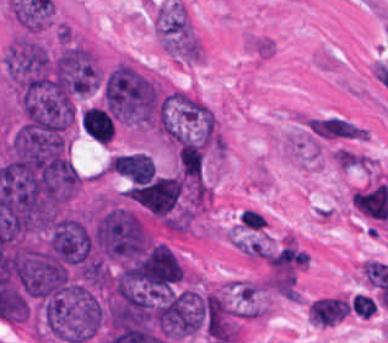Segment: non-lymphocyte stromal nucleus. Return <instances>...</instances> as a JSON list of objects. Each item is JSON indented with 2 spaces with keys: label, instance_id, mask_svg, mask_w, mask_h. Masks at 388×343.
I'll list each match as a JSON object with an SVG mask.
<instances>
[{
  "label": "non-lymphocyte stromal nucleus",
  "instance_id": "3",
  "mask_svg": "<svg viewBox=\"0 0 388 343\" xmlns=\"http://www.w3.org/2000/svg\"><path fill=\"white\" fill-rule=\"evenodd\" d=\"M308 125L313 135L323 139H361L360 127L341 118H310Z\"/></svg>",
  "mask_w": 388,
  "mask_h": 343
},
{
  "label": "non-lymphocyte stromal nucleus",
  "instance_id": "2",
  "mask_svg": "<svg viewBox=\"0 0 388 343\" xmlns=\"http://www.w3.org/2000/svg\"><path fill=\"white\" fill-rule=\"evenodd\" d=\"M349 308V302L339 297H319L312 301L306 316L310 323L330 327L338 322Z\"/></svg>",
  "mask_w": 388,
  "mask_h": 343
},
{
  "label": "non-lymphocyte stromal nucleus",
  "instance_id": "4",
  "mask_svg": "<svg viewBox=\"0 0 388 343\" xmlns=\"http://www.w3.org/2000/svg\"><path fill=\"white\" fill-rule=\"evenodd\" d=\"M350 308L361 319H368L373 314L376 306L372 299L356 292L350 297Z\"/></svg>",
  "mask_w": 388,
  "mask_h": 343
},
{
  "label": "non-lymphocyte stromal nucleus",
  "instance_id": "5",
  "mask_svg": "<svg viewBox=\"0 0 388 343\" xmlns=\"http://www.w3.org/2000/svg\"><path fill=\"white\" fill-rule=\"evenodd\" d=\"M240 223L244 230H261L266 226L265 217L250 209H243Z\"/></svg>",
  "mask_w": 388,
  "mask_h": 343
},
{
  "label": "non-lymphocyte stromal nucleus",
  "instance_id": "1",
  "mask_svg": "<svg viewBox=\"0 0 388 343\" xmlns=\"http://www.w3.org/2000/svg\"><path fill=\"white\" fill-rule=\"evenodd\" d=\"M155 33L176 60L196 61L199 42L190 18L179 0H166L155 11Z\"/></svg>",
  "mask_w": 388,
  "mask_h": 343
}]
</instances>
